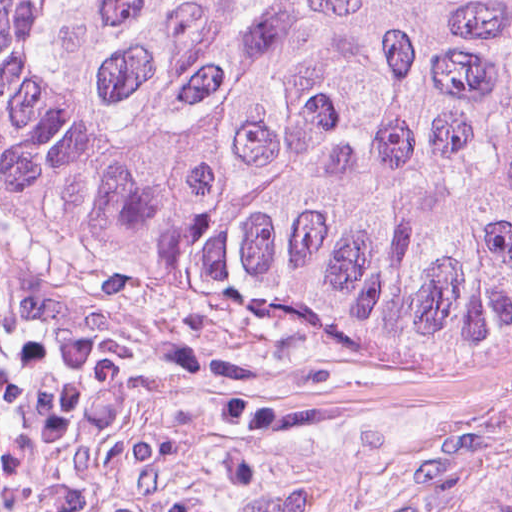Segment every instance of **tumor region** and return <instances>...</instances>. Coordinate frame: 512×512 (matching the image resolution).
Instances as JSON below:
<instances>
[{
  "mask_svg": "<svg viewBox=\"0 0 512 512\" xmlns=\"http://www.w3.org/2000/svg\"><path fill=\"white\" fill-rule=\"evenodd\" d=\"M0 166L59 247L442 352L512 321V0H0Z\"/></svg>",
  "mask_w": 512,
  "mask_h": 512,
  "instance_id": "e687c5a6",
  "label": "tumor region"
}]
</instances>
